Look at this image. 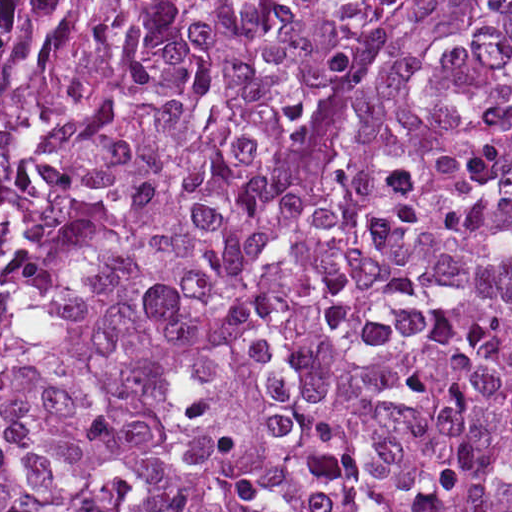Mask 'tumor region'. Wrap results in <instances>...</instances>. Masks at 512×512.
Listing matches in <instances>:
<instances>
[{"instance_id": "1", "label": "tumor region", "mask_w": 512, "mask_h": 512, "mask_svg": "<svg viewBox=\"0 0 512 512\" xmlns=\"http://www.w3.org/2000/svg\"><path fill=\"white\" fill-rule=\"evenodd\" d=\"M0 512H512V0H0Z\"/></svg>"}]
</instances>
